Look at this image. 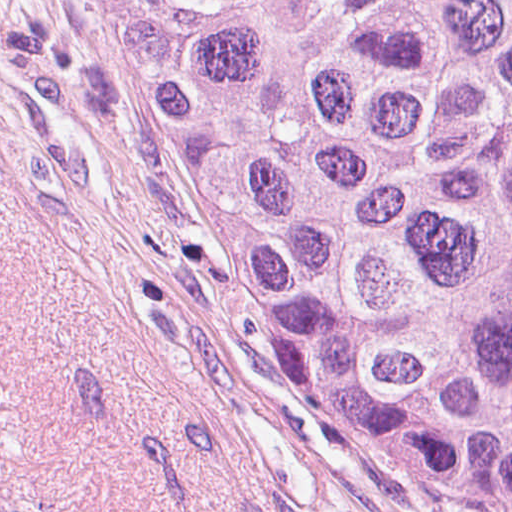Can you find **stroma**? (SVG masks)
<instances>
[{"label":"stroma","mask_w":512,"mask_h":512,"mask_svg":"<svg viewBox=\"0 0 512 512\" xmlns=\"http://www.w3.org/2000/svg\"><path fill=\"white\" fill-rule=\"evenodd\" d=\"M0 512H462L364 451L160 183L88 0H0Z\"/></svg>","instance_id":"obj_1"}]
</instances>
